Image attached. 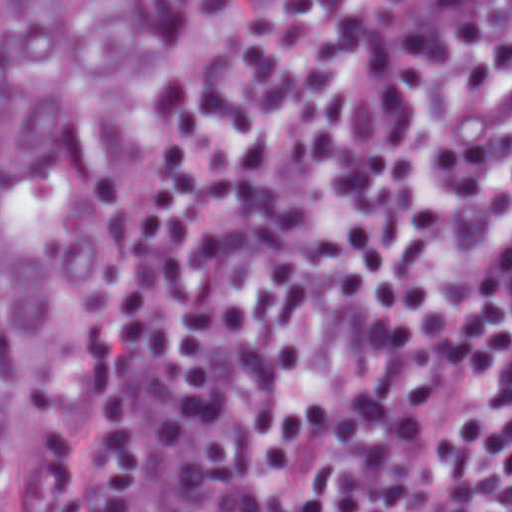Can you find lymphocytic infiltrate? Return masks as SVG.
<instances>
[{
  "label": "lymphocytic infiltrate",
  "mask_w": 512,
  "mask_h": 512,
  "mask_svg": "<svg viewBox=\"0 0 512 512\" xmlns=\"http://www.w3.org/2000/svg\"><path fill=\"white\" fill-rule=\"evenodd\" d=\"M5 512H512V1H251Z\"/></svg>",
  "instance_id": "lymphocytic-infiltrate-1"
}]
</instances>
